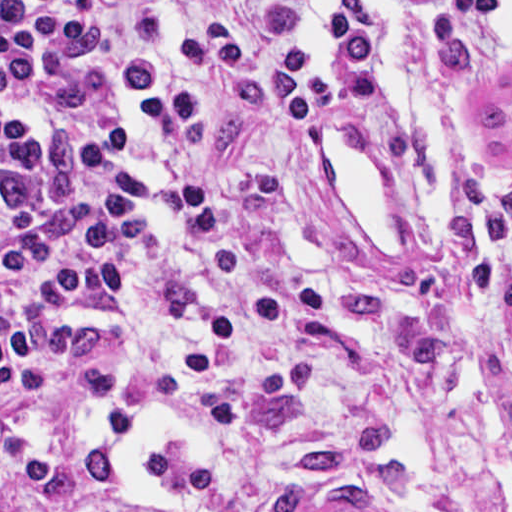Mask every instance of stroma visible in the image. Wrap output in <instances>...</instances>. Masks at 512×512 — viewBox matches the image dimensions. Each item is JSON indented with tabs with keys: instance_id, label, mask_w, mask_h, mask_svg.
Returning a JSON list of instances; mask_svg holds the SVG:
<instances>
[{
	"instance_id": "1",
	"label": "stroma",
	"mask_w": 512,
	"mask_h": 512,
	"mask_svg": "<svg viewBox=\"0 0 512 512\" xmlns=\"http://www.w3.org/2000/svg\"><path fill=\"white\" fill-rule=\"evenodd\" d=\"M438 66L467 139L436 243L364 241L315 129L366 124L383 84L304 128L281 156L248 238L273 274L326 290L320 317L269 357L214 474L224 512H257L279 458L348 408L374 416L411 476L377 512H512V54L496 0H447ZM376 43L386 45L379 14Z\"/></svg>"
}]
</instances>
